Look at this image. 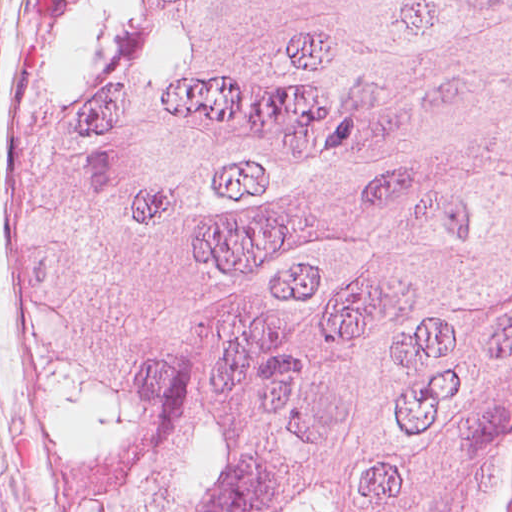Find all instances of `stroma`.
I'll return each mask as SVG.
<instances>
[{"mask_svg":"<svg viewBox=\"0 0 512 512\" xmlns=\"http://www.w3.org/2000/svg\"><path fill=\"white\" fill-rule=\"evenodd\" d=\"M44 0H0V512H77L37 378L21 246L22 125ZM512 392L501 403L471 512H502Z\"/></svg>","mask_w":512,"mask_h":512,"instance_id":"1","label":"stroma"}]
</instances>
